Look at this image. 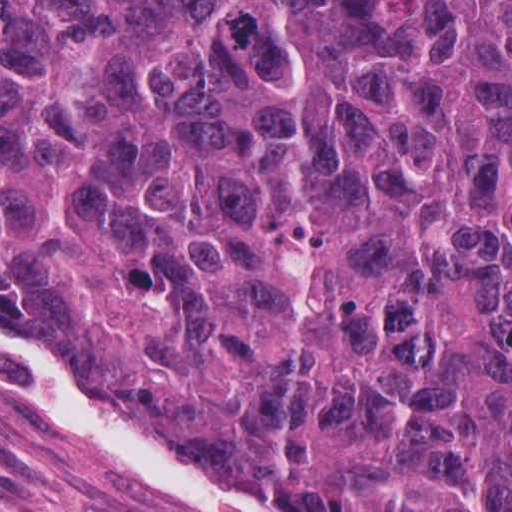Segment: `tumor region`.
I'll return each instance as SVG.
<instances>
[{
	"label": "tumor region",
	"mask_w": 512,
	"mask_h": 512,
	"mask_svg": "<svg viewBox=\"0 0 512 512\" xmlns=\"http://www.w3.org/2000/svg\"><path fill=\"white\" fill-rule=\"evenodd\" d=\"M0 316L294 512H512V0H0Z\"/></svg>",
	"instance_id": "tumor-region-1"
}]
</instances>
